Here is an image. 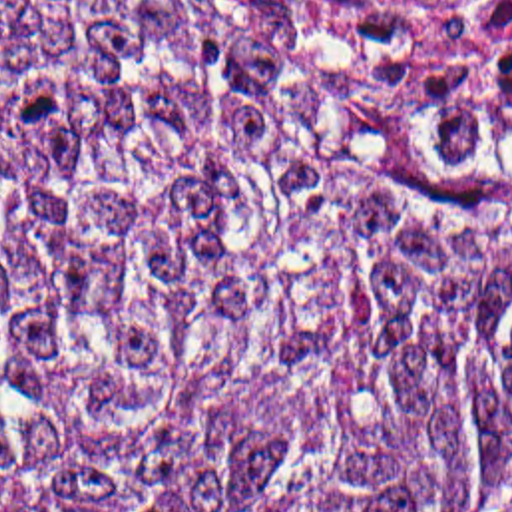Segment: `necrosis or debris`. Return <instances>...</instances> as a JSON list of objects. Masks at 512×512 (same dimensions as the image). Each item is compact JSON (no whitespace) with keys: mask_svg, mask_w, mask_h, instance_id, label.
Returning <instances> with one entry per match:
<instances>
[{"mask_svg":"<svg viewBox=\"0 0 512 512\" xmlns=\"http://www.w3.org/2000/svg\"><path fill=\"white\" fill-rule=\"evenodd\" d=\"M377 65L414 117L456 125L512 97V0H476L424 33L383 41Z\"/></svg>","mask_w":512,"mask_h":512,"instance_id":"1","label":"necrosis or debris"}]
</instances>
